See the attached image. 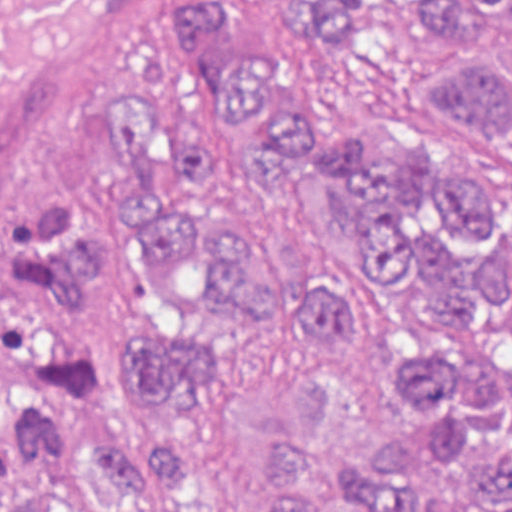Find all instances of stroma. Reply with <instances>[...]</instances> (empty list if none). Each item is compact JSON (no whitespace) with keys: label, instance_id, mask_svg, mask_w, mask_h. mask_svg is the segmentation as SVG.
Returning <instances> with one entry per match:
<instances>
[{"label":"stroma","instance_id":"stroma-1","mask_svg":"<svg viewBox=\"0 0 512 512\" xmlns=\"http://www.w3.org/2000/svg\"><path fill=\"white\" fill-rule=\"evenodd\" d=\"M244 53L298 47V19L267 0H229ZM172 0H152L70 75L44 122L0 171V512L23 496L102 512L88 485L50 478L12 454V405L23 390L66 394L90 421H132L189 437L192 512H255L265 484V426L293 410V382L310 359L339 371V428L352 459L409 433L382 374L388 348L416 342L431 316L406 300L371 254L321 232L244 160L217 172L249 198L272 255L293 275L353 291L378 321L349 343L319 321L260 322L236 345L206 398L183 421L120 410V375L133 347L187 326L149 243L120 249L93 281L82 311L52 326L31 305V275L9 255V225L33 202L88 193L109 214L136 204L109 114L126 86H154L182 114L199 93L170 37ZM446 42L381 16L354 46L306 51L293 81L318 142L369 131L387 155L436 141L442 154L499 192L512 220V152L482 136L412 80ZM496 321L512 328V312Z\"/></svg>","mask_w":512,"mask_h":512}]
</instances>
